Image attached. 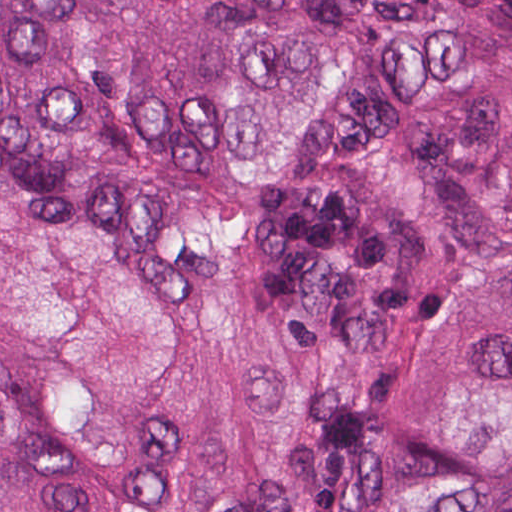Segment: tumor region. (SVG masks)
Masks as SVG:
<instances>
[{"instance_id":"obj_1","label":"tumor region","mask_w":512,"mask_h":512,"mask_svg":"<svg viewBox=\"0 0 512 512\" xmlns=\"http://www.w3.org/2000/svg\"><path fill=\"white\" fill-rule=\"evenodd\" d=\"M0 512H512V0H0Z\"/></svg>"}]
</instances>
